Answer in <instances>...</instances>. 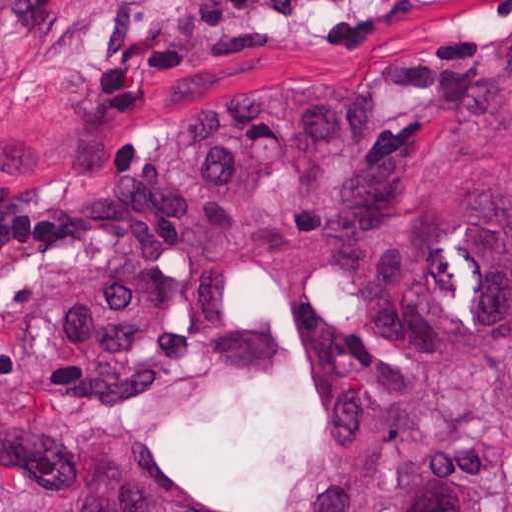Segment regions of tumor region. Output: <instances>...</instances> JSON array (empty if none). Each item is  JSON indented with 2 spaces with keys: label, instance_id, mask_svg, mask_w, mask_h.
<instances>
[{
  "label": "tumor region",
  "instance_id": "tumor-region-1",
  "mask_svg": "<svg viewBox=\"0 0 512 512\" xmlns=\"http://www.w3.org/2000/svg\"><path fill=\"white\" fill-rule=\"evenodd\" d=\"M360 118L281 85L130 165L0 181V512H232L153 429L213 423L277 360L231 311L265 269L320 366L272 512H512V0L426 39Z\"/></svg>",
  "mask_w": 512,
  "mask_h": 512
}]
</instances>
